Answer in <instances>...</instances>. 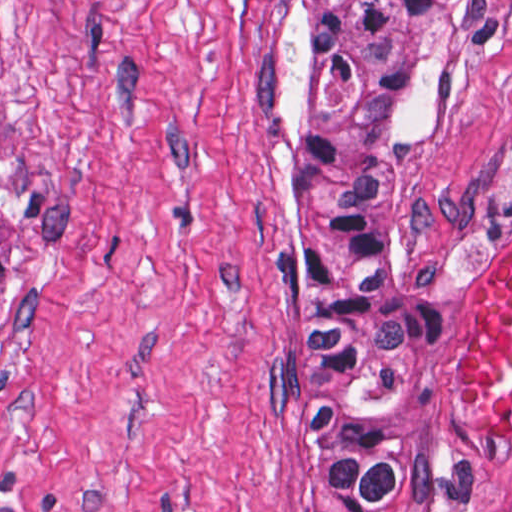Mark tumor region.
<instances>
[{
  "instance_id": "tumor-region-1",
  "label": "tumor region",
  "mask_w": 512,
  "mask_h": 512,
  "mask_svg": "<svg viewBox=\"0 0 512 512\" xmlns=\"http://www.w3.org/2000/svg\"><path fill=\"white\" fill-rule=\"evenodd\" d=\"M478 0H296L288 134V376L325 512L408 497L440 325L384 264L380 179L456 87ZM8 299L0 210V312Z\"/></svg>"
}]
</instances>
